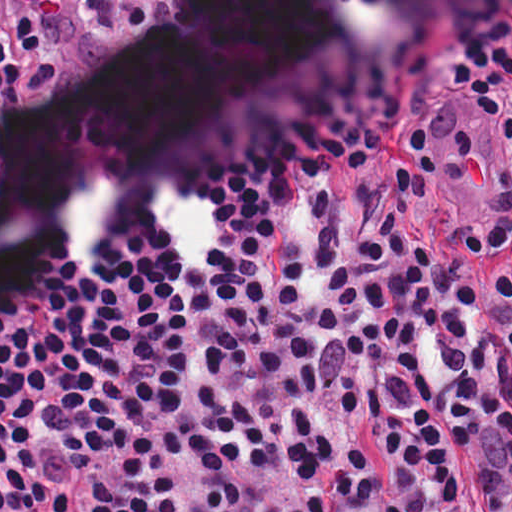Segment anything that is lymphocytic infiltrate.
I'll return each instance as SVG.
<instances>
[{
    "instance_id": "f902f5d3",
    "label": "lymphocytic infiltrate",
    "mask_w": 512,
    "mask_h": 512,
    "mask_svg": "<svg viewBox=\"0 0 512 512\" xmlns=\"http://www.w3.org/2000/svg\"><path fill=\"white\" fill-rule=\"evenodd\" d=\"M486 512H512V432L465 452ZM456 457L332 512H442L455 501Z\"/></svg>"
}]
</instances>
